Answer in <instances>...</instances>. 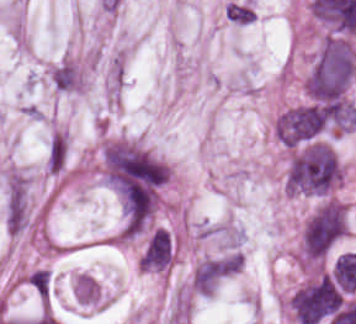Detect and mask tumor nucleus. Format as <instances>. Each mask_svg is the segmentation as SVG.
<instances>
[{
  "label": "tumor nucleus",
  "instance_id": "obj_5",
  "mask_svg": "<svg viewBox=\"0 0 356 324\" xmlns=\"http://www.w3.org/2000/svg\"><path fill=\"white\" fill-rule=\"evenodd\" d=\"M343 294L332 276L320 274L300 287L290 306L303 324H317L340 308Z\"/></svg>",
  "mask_w": 356,
  "mask_h": 324
},
{
  "label": "tumor nucleus",
  "instance_id": "obj_3",
  "mask_svg": "<svg viewBox=\"0 0 356 324\" xmlns=\"http://www.w3.org/2000/svg\"><path fill=\"white\" fill-rule=\"evenodd\" d=\"M338 104L309 101L283 111L276 121L277 137L281 142L298 145L338 123Z\"/></svg>",
  "mask_w": 356,
  "mask_h": 324
},
{
  "label": "tumor nucleus",
  "instance_id": "obj_4",
  "mask_svg": "<svg viewBox=\"0 0 356 324\" xmlns=\"http://www.w3.org/2000/svg\"><path fill=\"white\" fill-rule=\"evenodd\" d=\"M346 229V207L325 202L309 218L303 229V258L320 261L342 237Z\"/></svg>",
  "mask_w": 356,
  "mask_h": 324
},
{
  "label": "tumor nucleus",
  "instance_id": "obj_2",
  "mask_svg": "<svg viewBox=\"0 0 356 324\" xmlns=\"http://www.w3.org/2000/svg\"><path fill=\"white\" fill-rule=\"evenodd\" d=\"M340 175V164L326 142L309 141L290 159L284 186L290 192L326 195Z\"/></svg>",
  "mask_w": 356,
  "mask_h": 324
},
{
  "label": "tumor nucleus",
  "instance_id": "obj_9",
  "mask_svg": "<svg viewBox=\"0 0 356 324\" xmlns=\"http://www.w3.org/2000/svg\"><path fill=\"white\" fill-rule=\"evenodd\" d=\"M28 281L41 298L48 300L51 292L50 271L43 268H36L29 275Z\"/></svg>",
  "mask_w": 356,
  "mask_h": 324
},
{
  "label": "tumor nucleus",
  "instance_id": "obj_6",
  "mask_svg": "<svg viewBox=\"0 0 356 324\" xmlns=\"http://www.w3.org/2000/svg\"><path fill=\"white\" fill-rule=\"evenodd\" d=\"M174 255L171 233L166 228L154 230L141 256V263L146 269H166Z\"/></svg>",
  "mask_w": 356,
  "mask_h": 324
},
{
  "label": "tumor nucleus",
  "instance_id": "obj_8",
  "mask_svg": "<svg viewBox=\"0 0 356 324\" xmlns=\"http://www.w3.org/2000/svg\"><path fill=\"white\" fill-rule=\"evenodd\" d=\"M77 300L84 303H95L99 297L100 289L92 276L81 274L75 283Z\"/></svg>",
  "mask_w": 356,
  "mask_h": 324
},
{
  "label": "tumor nucleus",
  "instance_id": "obj_1",
  "mask_svg": "<svg viewBox=\"0 0 356 324\" xmlns=\"http://www.w3.org/2000/svg\"><path fill=\"white\" fill-rule=\"evenodd\" d=\"M356 71V52L346 38L329 36L320 48L305 85L311 100L335 101L348 89Z\"/></svg>",
  "mask_w": 356,
  "mask_h": 324
},
{
  "label": "tumor nucleus",
  "instance_id": "obj_7",
  "mask_svg": "<svg viewBox=\"0 0 356 324\" xmlns=\"http://www.w3.org/2000/svg\"><path fill=\"white\" fill-rule=\"evenodd\" d=\"M230 270L226 257L204 260L193 274V285L199 293H209Z\"/></svg>",
  "mask_w": 356,
  "mask_h": 324
}]
</instances>
